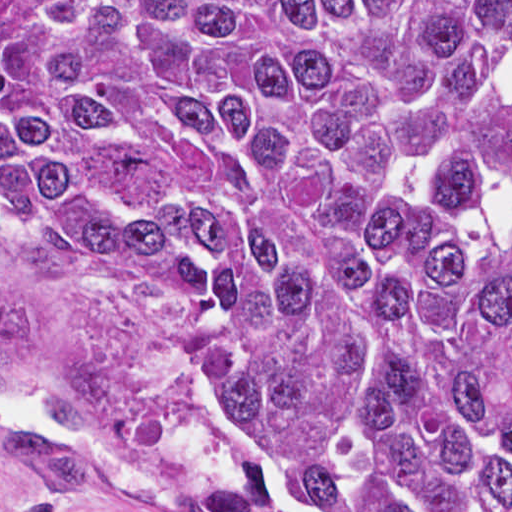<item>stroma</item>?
Returning a JSON list of instances; mask_svg holds the SVG:
<instances>
[{"mask_svg": "<svg viewBox=\"0 0 512 512\" xmlns=\"http://www.w3.org/2000/svg\"><path fill=\"white\" fill-rule=\"evenodd\" d=\"M0 1H512V0H0ZM0 295L32 311L35 332L16 365L39 370L67 354L91 351L112 370V394L82 430L56 421L45 391L8 396L35 404L41 424L73 434L97 465L72 481L64 512H199V495L219 481L168 440L181 403L165 388L121 323L0 237ZM7 396V395H6ZM0 421V512H21L34 485L14 462ZM33 428V427H31Z\"/></svg>", "mask_w": 512, "mask_h": 512, "instance_id": "35a3bbf8", "label": "stroma"}]
</instances>
